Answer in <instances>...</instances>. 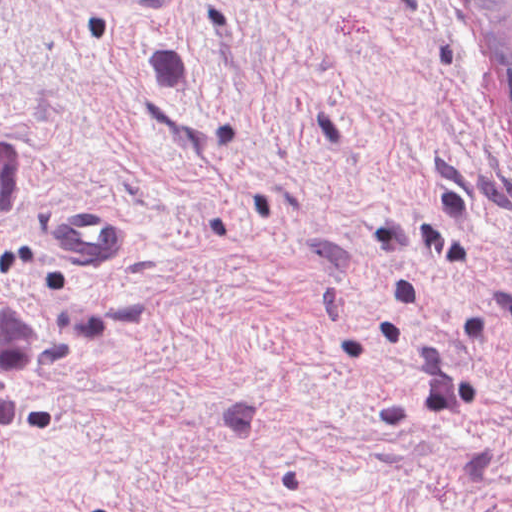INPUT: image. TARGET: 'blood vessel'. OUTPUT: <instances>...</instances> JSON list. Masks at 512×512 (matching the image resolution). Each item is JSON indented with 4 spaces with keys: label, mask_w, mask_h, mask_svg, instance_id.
<instances>
[{
    "label": "blood vessel",
    "mask_w": 512,
    "mask_h": 512,
    "mask_svg": "<svg viewBox=\"0 0 512 512\" xmlns=\"http://www.w3.org/2000/svg\"><path fill=\"white\" fill-rule=\"evenodd\" d=\"M63 244L91 268H132L136 240L127 227L101 210H73L61 218Z\"/></svg>",
    "instance_id": "blood-vessel-1"
}]
</instances>
